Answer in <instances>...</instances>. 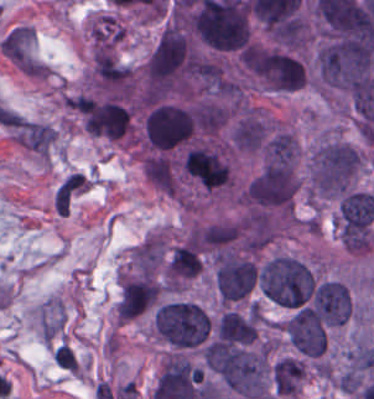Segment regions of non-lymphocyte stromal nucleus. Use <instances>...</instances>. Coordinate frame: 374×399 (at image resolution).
Masks as SVG:
<instances>
[{
  "label": "non-lymphocyte stromal nucleus",
  "instance_id": "non-lymphocyte-stromal-nucleus-1",
  "mask_svg": "<svg viewBox=\"0 0 374 399\" xmlns=\"http://www.w3.org/2000/svg\"><path fill=\"white\" fill-rule=\"evenodd\" d=\"M64 322V307L58 296H50L39 306L38 329L49 342L61 333Z\"/></svg>",
  "mask_w": 374,
  "mask_h": 399
},
{
  "label": "non-lymphocyte stromal nucleus",
  "instance_id": "non-lymphocyte-stromal-nucleus-2",
  "mask_svg": "<svg viewBox=\"0 0 374 399\" xmlns=\"http://www.w3.org/2000/svg\"><path fill=\"white\" fill-rule=\"evenodd\" d=\"M87 179L80 172H73L54 194L55 210H69L86 190Z\"/></svg>",
  "mask_w": 374,
  "mask_h": 399
}]
</instances>
